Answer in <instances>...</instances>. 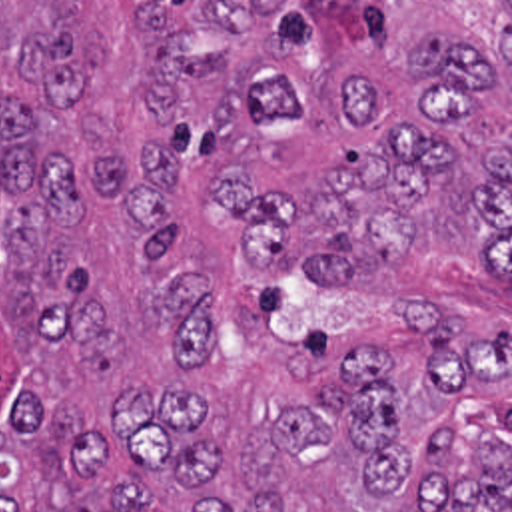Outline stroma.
<instances>
[{
	"label": "stroma",
	"mask_w": 512,
	"mask_h": 512,
	"mask_svg": "<svg viewBox=\"0 0 512 512\" xmlns=\"http://www.w3.org/2000/svg\"><path fill=\"white\" fill-rule=\"evenodd\" d=\"M0 2H512V0H0ZM484 120L512 132V76L482 90ZM436 303L466 319V341L496 327L512 329V285L482 275L476 268H452L438 258H406L378 277L346 287H320L287 277L279 281L273 309L279 327H326L338 343H362L374 349H418L424 343L412 327L400 323L404 303ZM512 441V385L502 393L466 387L456 405L458 459L470 469V457L488 433Z\"/></svg>",
	"instance_id": "35a3bbf8"
}]
</instances>
